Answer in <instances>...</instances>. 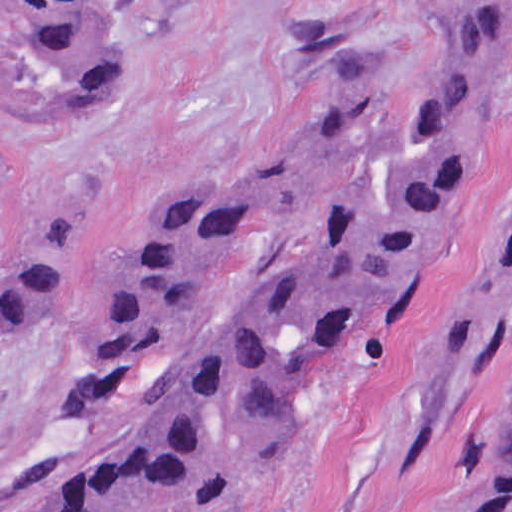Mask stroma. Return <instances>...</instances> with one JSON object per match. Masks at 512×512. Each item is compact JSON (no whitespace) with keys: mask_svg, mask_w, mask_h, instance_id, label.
<instances>
[{"mask_svg":"<svg viewBox=\"0 0 512 512\" xmlns=\"http://www.w3.org/2000/svg\"><path fill=\"white\" fill-rule=\"evenodd\" d=\"M58 0H0V171L28 231L71 205L72 278L0 346V512H71L67 479L109 295L208 195L311 134L423 49L456 0H178L104 115L44 120L31 46ZM142 6L145 0H137ZM512 0L471 175L420 277L325 355L275 435L180 512H484L512 393Z\"/></svg>","mask_w":512,"mask_h":512,"instance_id":"stroma-1","label":"stroma"}]
</instances>
